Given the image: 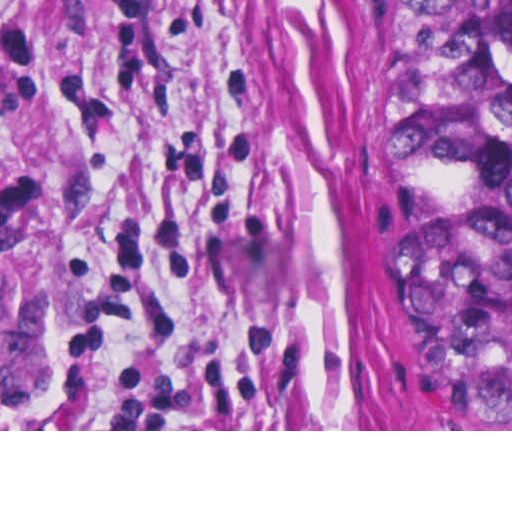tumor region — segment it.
Here are the masks:
<instances>
[{
  "instance_id": "e687c5a6",
  "label": "tumor region",
  "mask_w": 512,
  "mask_h": 512,
  "mask_svg": "<svg viewBox=\"0 0 512 512\" xmlns=\"http://www.w3.org/2000/svg\"><path fill=\"white\" fill-rule=\"evenodd\" d=\"M410 98L391 429H512V0H398Z\"/></svg>"
}]
</instances>
